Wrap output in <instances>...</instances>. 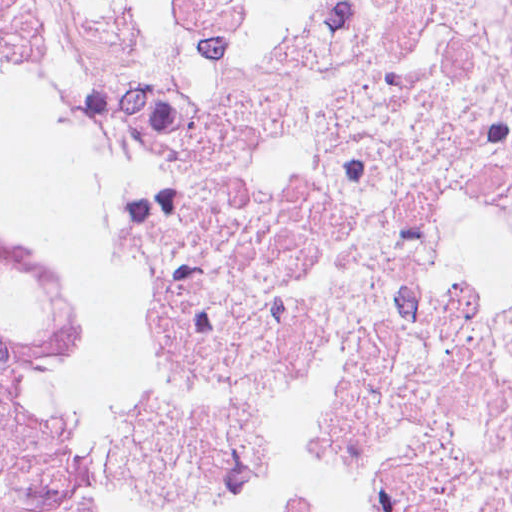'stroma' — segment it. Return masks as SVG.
Returning a JSON list of instances; mask_svg holds the SVG:
<instances>
[{
	"label": "stroma",
	"mask_w": 512,
	"mask_h": 512,
	"mask_svg": "<svg viewBox=\"0 0 512 512\" xmlns=\"http://www.w3.org/2000/svg\"><path fill=\"white\" fill-rule=\"evenodd\" d=\"M0 52L35 78L93 102L127 156L141 227L162 272L163 332L124 425L95 460L67 470V494L76 512H144L173 382L194 343L235 328L243 289L219 257L179 234L150 191L127 103L86 23L57 0H0ZM73 383L71 365L59 398L63 426Z\"/></svg>",
	"instance_id": "stroma-1"
}]
</instances>
